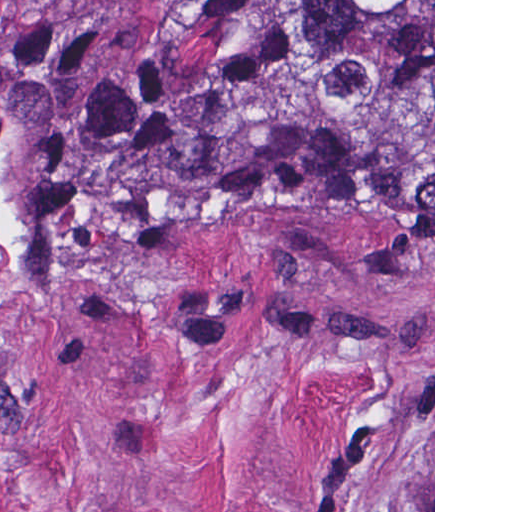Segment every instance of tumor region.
<instances>
[{"label":"tumor region","mask_w":512,"mask_h":512,"mask_svg":"<svg viewBox=\"0 0 512 512\" xmlns=\"http://www.w3.org/2000/svg\"><path fill=\"white\" fill-rule=\"evenodd\" d=\"M433 221V0H208L114 50H0V355L50 269L341 166Z\"/></svg>","instance_id":"tumor-region-1"}]
</instances>
